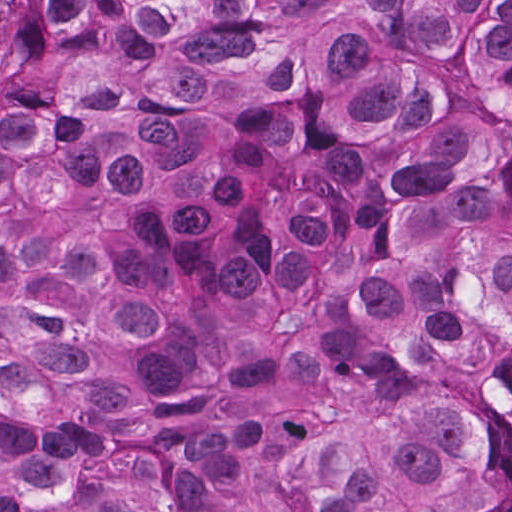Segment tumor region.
<instances>
[{"label": "tumor region", "mask_w": 512, "mask_h": 512, "mask_svg": "<svg viewBox=\"0 0 512 512\" xmlns=\"http://www.w3.org/2000/svg\"><path fill=\"white\" fill-rule=\"evenodd\" d=\"M0 512H512V0H0Z\"/></svg>", "instance_id": "obj_1"}]
</instances>
